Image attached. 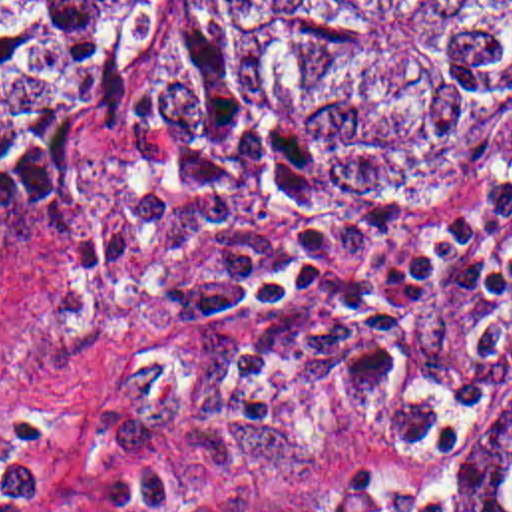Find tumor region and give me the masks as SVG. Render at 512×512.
<instances>
[{
	"instance_id": "obj_1",
	"label": "tumor region",
	"mask_w": 512,
	"mask_h": 512,
	"mask_svg": "<svg viewBox=\"0 0 512 512\" xmlns=\"http://www.w3.org/2000/svg\"><path fill=\"white\" fill-rule=\"evenodd\" d=\"M148 0H0V227L89 219ZM266 99L339 201H391L512 99V0H170L134 99L164 167L220 103ZM457 512H512V402Z\"/></svg>"
}]
</instances>
